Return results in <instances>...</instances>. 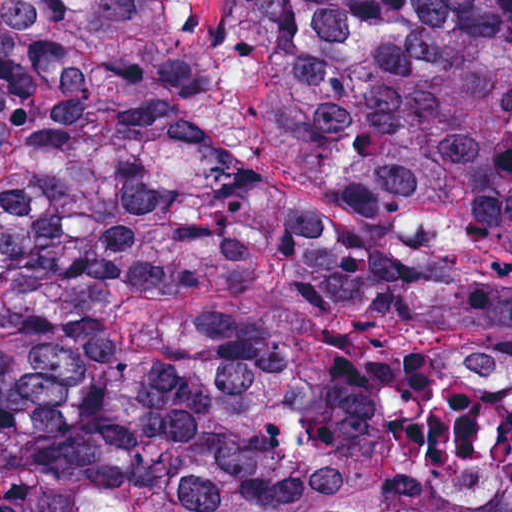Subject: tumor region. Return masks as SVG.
Instances as JSON below:
<instances>
[{
	"mask_svg": "<svg viewBox=\"0 0 512 512\" xmlns=\"http://www.w3.org/2000/svg\"><path fill=\"white\" fill-rule=\"evenodd\" d=\"M0 0V512H512V0Z\"/></svg>",
	"mask_w": 512,
	"mask_h": 512,
	"instance_id": "obj_1",
	"label": "tumor region"
}]
</instances>
